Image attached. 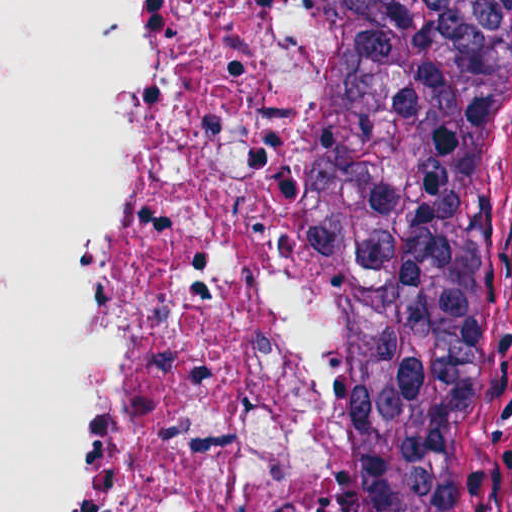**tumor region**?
<instances>
[{
    "mask_svg": "<svg viewBox=\"0 0 512 512\" xmlns=\"http://www.w3.org/2000/svg\"><path fill=\"white\" fill-rule=\"evenodd\" d=\"M312 512H433L498 165L512 0H302Z\"/></svg>",
    "mask_w": 512,
    "mask_h": 512,
    "instance_id": "e687c5a6",
    "label": "tumor region"
}]
</instances>
